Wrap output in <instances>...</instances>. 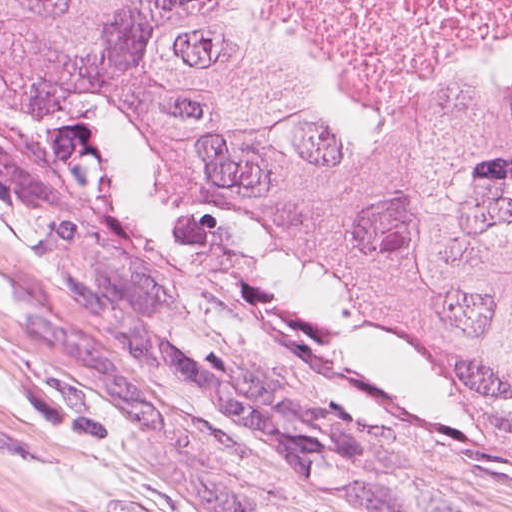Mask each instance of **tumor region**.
<instances>
[{
  "mask_svg": "<svg viewBox=\"0 0 512 512\" xmlns=\"http://www.w3.org/2000/svg\"><path fill=\"white\" fill-rule=\"evenodd\" d=\"M0 89L105 103L152 169L512 410V43L339 91L222 0H0Z\"/></svg>",
  "mask_w": 512,
  "mask_h": 512,
  "instance_id": "obj_1",
  "label": "tumor region"
}]
</instances>
